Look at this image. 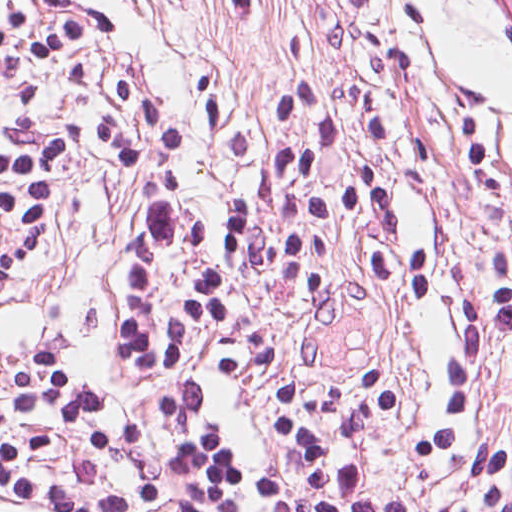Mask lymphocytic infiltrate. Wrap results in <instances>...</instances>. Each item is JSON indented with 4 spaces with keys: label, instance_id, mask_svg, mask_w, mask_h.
<instances>
[{
    "label": "lymphocytic infiltrate",
    "instance_id": "lymphocytic-infiltrate-1",
    "mask_svg": "<svg viewBox=\"0 0 512 512\" xmlns=\"http://www.w3.org/2000/svg\"><path fill=\"white\" fill-rule=\"evenodd\" d=\"M269 154L220 224L187 190L173 108L82 0H0V276L64 243L65 180L87 155L132 177L120 228L123 384L20 352L0 370V501L35 512H512V434L440 379L407 479L367 482L402 412L394 377L271 392L260 472L224 412L296 331L423 258L428 195L388 112L330 73L268 71ZM241 73L214 56L193 103L210 140ZM462 339L512 341V287L462 293Z\"/></svg>",
    "mask_w": 512,
    "mask_h": 512
}]
</instances>
